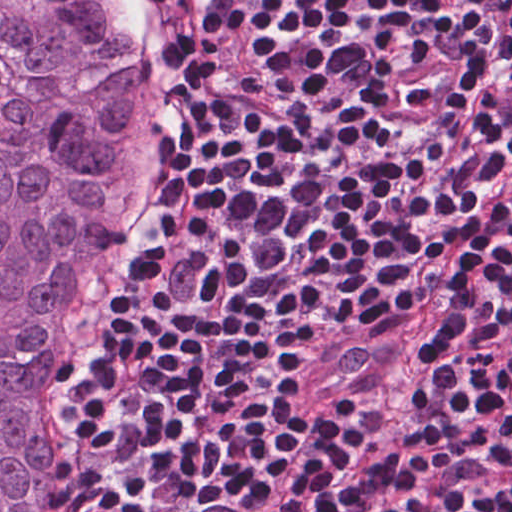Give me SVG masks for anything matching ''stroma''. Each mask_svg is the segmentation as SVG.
Segmentation results:
<instances>
[{"label": "stroma", "mask_w": 512, "mask_h": 512, "mask_svg": "<svg viewBox=\"0 0 512 512\" xmlns=\"http://www.w3.org/2000/svg\"><path fill=\"white\" fill-rule=\"evenodd\" d=\"M140 3L145 7V9L149 12L153 24L160 36L164 49L166 51V31L163 22V18L161 16L160 10L155 2V0H139ZM176 114V107L174 96L172 94V77H171V115L174 116ZM102 373V372H101ZM101 379V374L81 393V403H82V412L79 408V421H78V433H77V451L80 445V441L88 420V416L96 395V391Z\"/></svg>", "instance_id": "obj_1"}]
</instances>
